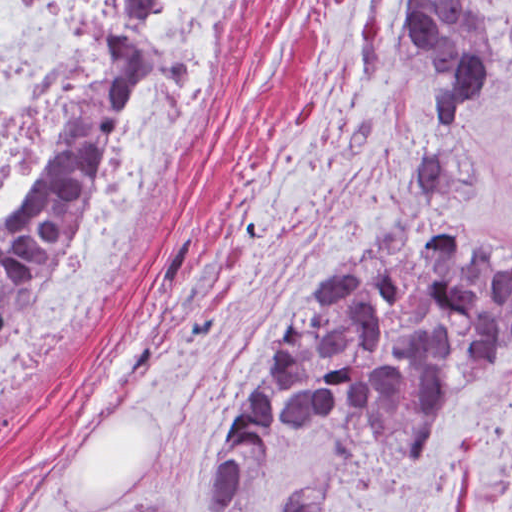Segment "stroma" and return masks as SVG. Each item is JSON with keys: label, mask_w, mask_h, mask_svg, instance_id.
Instances as JSON below:
<instances>
[{"label": "stroma", "mask_w": 512, "mask_h": 512, "mask_svg": "<svg viewBox=\"0 0 512 512\" xmlns=\"http://www.w3.org/2000/svg\"><path fill=\"white\" fill-rule=\"evenodd\" d=\"M401 1H484L507 27L502 73L461 131L430 119L387 38ZM431 152L443 228L512 251V0H249L127 305L0 410V512H116L160 495L201 512L277 318L379 227ZM307 488L329 490L317 512H512V347L423 446L377 436L357 451L337 425L274 434L227 512H281L280 495Z\"/></svg>", "instance_id": "stroma-1"}]
</instances>
